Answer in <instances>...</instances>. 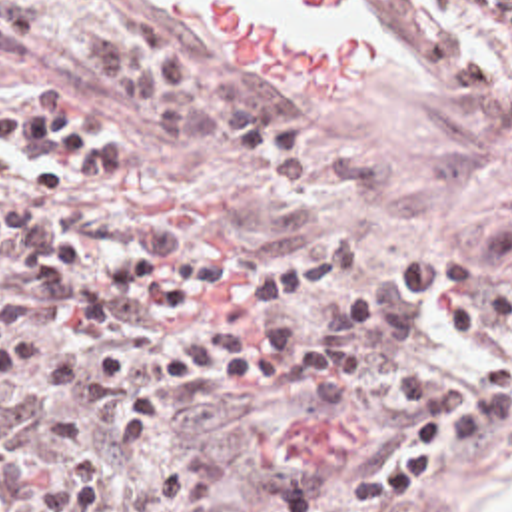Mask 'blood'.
Returning <instances> with one entry per match:
<instances>
[{
  "mask_svg": "<svg viewBox=\"0 0 512 512\" xmlns=\"http://www.w3.org/2000/svg\"><path fill=\"white\" fill-rule=\"evenodd\" d=\"M205 28L225 70L263 76L269 86H342L376 70V42L324 26H287L247 0H177ZM310 14H346L354 0H267Z\"/></svg>",
  "mask_w": 512,
  "mask_h": 512,
  "instance_id": "1",
  "label": "blood"
}]
</instances>
